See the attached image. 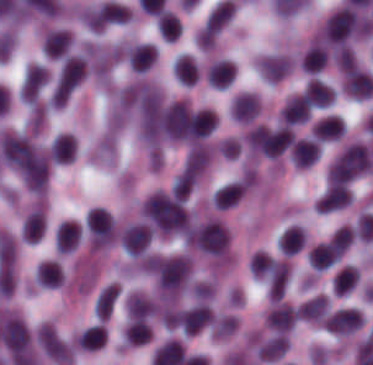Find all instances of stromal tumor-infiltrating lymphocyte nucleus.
I'll list each match as a JSON object with an SVG mask.
<instances>
[{
  "label": "stromal tumor-infiltrating lymphocyte nucleus",
  "mask_w": 373,
  "mask_h": 365,
  "mask_svg": "<svg viewBox=\"0 0 373 365\" xmlns=\"http://www.w3.org/2000/svg\"><path fill=\"white\" fill-rule=\"evenodd\" d=\"M34 280L45 287H58L63 282V269L57 259H44L36 265Z\"/></svg>",
  "instance_id": "obj_20"
},
{
  "label": "stromal tumor-infiltrating lymphocyte nucleus",
  "mask_w": 373,
  "mask_h": 365,
  "mask_svg": "<svg viewBox=\"0 0 373 365\" xmlns=\"http://www.w3.org/2000/svg\"><path fill=\"white\" fill-rule=\"evenodd\" d=\"M88 70L87 58L82 54L70 53L61 69L54 95L58 100H68Z\"/></svg>",
  "instance_id": "obj_3"
},
{
  "label": "stromal tumor-infiltrating lymphocyte nucleus",
  "mask_w": 373,
  "mask_h": 365,
  "mask_svg": "<svg viewBox=\"0 0 373 365\" xmlns=\"http://www.w3.org/2000/svg\"><path fill=\"white\" fill-rule=\"evenodd\" d=\"M296 319V309L289 302H276L265 317V323L276 333H287Z\"/></svg>",
  "instance_id": "obj_11"
},
{
  "label": "stromal tumor-infiltrating lymphocyte nucleus",
  "mask_w": 373,
  "mask_h": 365,
  "mask_svg": "<svg viewBox=\"0 0 373 365\" xmlns=\"http://www.w3.org/2000/svg\"><path fill=\"white\" fill-rule=\"evenodd\" d=\"M198 173L199 170L187 163L177 174L172 184V195L185 198L195 186Z\"/></svg>",
  "instance_id": "obj_25"
},
{
  "label": "stromal tumor-infiltrating lymphocyte nucleus",
  "mask_w": 373,
  "mask_h": 365,
  "mask_svg": "<svg viewBox=\"0 0 373 365\" xmlns=\"http://www.w3.org/2000/svg\"><path fill=\"white\" fill-rule=\"evenodd\" d=\"M47 74L48 69L41 64H28L19 90L25 103L35 106L47 81Z\"/></svg>",
  "instance_id": "obj_5"
},
{
  "label": "stromal tumor-infiltrating lymphocyte nucleus",
  "mask_w": 373,
  "mask_h": 365,
  "mask_svg": "<svg viewBox=\"0 0 373 365\" xmlns=\"http://www.w3.org/2000/svg\"><path fill=\"white\" fill-rule=\"evenodd\" d=\"M81 229L77 221H63L55 231L57 253H70L77 249L81 239Z\"/></svg>",
  "instance_id": "obj_14"
},
{
  "label": "stromal tumor-infiltrating lymphocyte nucleus",
  "mask_w": 373,
  "mask_h": 365,
  "mask_svg": "<svg viewBox=\"0 0 373 365\" xmlns=\"http://www.w3.org/2000/svg\"><path fill=\"white\" fill-rule=\"evenodd\" d=\"M343 132V120L340 115L328 113L311 126V137L321 141L337 139Z\"/></svg>",
  "instance_id": "obj_18"
},
{
  "label": "stromal tumor-infiltrating lymphocyte nucleus",
  "mask_w": 373,
  "mask_h": 365,
  "mask_svg": "<svg viewBox=\"0 0 373 365\" xmlns=\"http://www.w3.org/2000/svg\"><path fill=\"white\" fill-rule=\"evenodd\" d=\"M210 157L211 147L205 142H198L189 149L184 164L201 174L208 166Z\"/></svg>",
  "instance_id": "obj_28"
},
{
  "label": "stromal tumor-infiltrating lymphocyte nucleus",
  "mask_w": 373,
  "mask_h": 365,
  "mask_svg": "<svg viewBox=\"0 0 373 365\" xmlns=\"http://www.w3.org/2000/svg\"><path fill=\"white\" fill-rule=\"evenodd\" d=\"M320 142L312 137H299L292 144V160L297 168H308L319 158Z\"/></svg>",
  "instance_id": "obj_10"
},
{
  "label": "stromal tumor-infiltrating lymphocyte nucleus",
  "mask_w": 373,
  "mask_h": 365,
  "mask_svg": "<svg viewBox=\"0 0 373 365\" xmlns=\"http://www.w3.org/2000/svg\"><path fill=\"white\" fill-rule=\"evenodd\" d=\"M327 313V296L318 293L300 305L297 316L309 321H322Z\"/></svg>",
  "instance_id": "obj_24"
},
{
  "label": "stromal tumor-infiltrating lymphocyte nucleus",
  "mask_w": 373,
  "mask_h": 365,
  "mask_svg": "<svg viewBox=\"0 0 373 365\" xmlns=\"http://www.w3.org/2000/svg\"><path fill=\"white\" fill-rule=\"evenodd\" d=\"M238 326L236 318L229 313H221L214 319L212 333L214 338H224Z\"/></svg>",
  "instance_id": "obj_30"
},
{
  "label": "stromal tumor-infiltrating lymphocyte nucleus",
  "mask_w": 373,
  "mask_h": 365,
  "mask_svg": "<svg viewBox=\"0 0 373 365\" xmlns=\"http://www.w3.org/2000/svg\"><path fill=\"white\" fill-rule=\"evenodd\" d=\"M311 111V105L303 92H295L281 106L278 119L285 124L296 125L306 120Z\"/></svg>",
  "instance_id": "obj_7"
},
{
  "label": "stromal tumor-infiltrating lymphocyte nucleus",
  "mask_w": 373,
  "mask_h": 365,
  "mask_svg": "<svg viewBox=\"0 0 373 365\" xmlns=\"http://www.w3.org/2000/svg\"><path fill=\"white\" fill-rule=\"evenodd\" d=\"M305 245V235L299 225H292L282 232L277 248L282 254L292 255L303 249Z\"/></svg>",
  "instance_id": "obj_21"
},
{
  "label": "stromal tumor-infiltrating lymphocyte nucleus",
  "mask_w": 373,
  "mask_h": 365,
  "mask_svg": "<svg viewBox=\"0 0 373 365\" xmlns=\"http://www.w3.org/2000/svg\"><path fill=\"white\" fill-rule=\"evenodd\" d=\"M77 137L72 132H58L49 147L51 161L68 163L76 155Z\"/></svg>",
  "instance_id": "obj_13"
},
{
  "label": "stromal tumor-infiltrating lymphocyte nucleus",
  "mask_w": 373,
  "mask_h": 365,
  "mask_svg": "<svg viewBox=\"0 0 373 365\" xmlns=\"http://www.w3.org/2000/svg\"><path fill=\"white\" fill-rule=\"evenodd\" d=\"M36 343L43 352L61 365H71L73 359L72 343L52 323L45 322L35 331Z\"/></svg>",
  "instance_id": "obj_2"
},
{
  "label": "stromal tumor-infiltrating lymphocyte nucleus",
  "mask_w": 373,
  "mask_h": 365,
  "mask_svg": "<svg viewBox=\"0 0 373 365\" xmlns=\"http://www.w3.org/2000/svg\"><path fill=\"white\" fill-rule=\"evenodd\" d=\"M105 342V328L101 323H94L78 333L76 344L86 350L100 348Z\"/></svg>",
  "instance_id": "obj_26"
},
{
  "label": "stromal tumor-infiltrating lymphocyte nucleus",
  "mask_w": 373,
  "mask_h": 365,
  "mask_svg": "<svg viewBox=\"0 0 373 365\" xmlns=\"http://www.w3.org/2000/svg\"><path fill=\"white\" fill-rule=\"evenodd\" d=\"M291 274L289 260L276 259L268 277V296L270 300H280Z\"/></svg>",
  "instance_id": "obj_16"
},
{
  "label": "stromal tumor-infiltrating lymphocyte nucleus",
  "mask_w": 373,
  "mask_h": 365,
  "mask_svg": "<svg viewBox=\"0 0 373 365\" xmlns=\"http://www.w3.org/2000/svg\"><path fill=\"white\" fill-rule=\"evenodd\" d=\"M340 259V252L329 239L316 243L308 252V262L315 269H324L335 264Z\"/></svg>",
  "instance_id": "obj_19"
},
{
  "label": "stromal tumor-infiltrating lymphocyte nucleus",
  "mask_w": 373,
  "mask_h": 365,
  "mask_svg": "<svg viewBox=\"0 0 373 365\" xmlns=\"http://www.w3.org/2000/svg\"><path fill=\"white\" fill-rule=\"evenodd\" d=\"M120 241L124 253L138 256L143 253L152 240V228L143 222H136L123 228Z\"/></svg>",
  "instance_id": "obj_4"
},
{
  "label": "stromal tumor-infiltrating lymphocyte nucleus",
  "mask_w": 373,
  "mask_h": 365,
  "mask_svg": "<svg viewBox=\"0 0 373 365\" xmlns=\"http://www.w3.org/2000/svg\"><path fill=\"white\" fill-rule=\"evenodd\" d=\"M352 202V192L348 185L332 184L327 187L314 204L320 212H330Z\"/></svg>",
  "instance_id": "obj_9"
},
{
  "label": "stromal tumor-infiltrating lymphocyte nucleus",
  "mask_w": 373,
  "mask_h": 365,
  "mask_svg": "<svg viewBox=\"0 0 373 365\" xmlns=\"http://www.w3.org/2000/svg\"><path fill=\"white\" fill-rule=\"evenodd\" d=\"M250 185L249 178L244 177L234 180L215 190L213 205L221 208L235 206L245 194Z\"/></svg>",
  "instance_id": "obj_15"
},
{
  "label": "stromal tumor-infiltrating lymphocyte nucleus",
  "mask_w": 373,
  "mask_h": 365,
  "mask_svg": "<svg viewBox=\"0 0 373 365\" xmlns=\"http://www.w3.org/2000/svg\"><path fill=\"white\" fill-rule=\"evenodd\" d=\"M261 107V97L254 91H241L234 99L231 116L237 121L252 122Z\"/></svg>",
  "instance_id": "obj_8"
},
{
  "label": "stromal tumor-infiltrating lymphocyte nucleus",
  "mask_w": 373,
  "mask_h": 365,
  "mask_svg": "<svg viewBox=\"0 0 373 365\" xmlns=\"http://www.w3.org/2000/svg\"><path fill=\"white\" fill-rule=\"evenodd\" d=\"M324 322L335 334H349L363 324V313L358 308L345 306L326 316Z\"/></svg>",
  "instance_id": "obj_6"
},
{
  "label": "stromal tumor-infiltrating lymphocyte nucleus",
  "mask_w": 373,
  "mask_h": 365,
  "mask_svg": "<svg viewBox=\"0 0 373 365\" xmlns=\"http://www.w3.org/2000/svg\"><path fill=\"white\" fill-rule=\"evenodd\" d=\"M207 81L215 87H229L236 77L235 63L230 59H216L205 72Z\"/></svg>",
  "instance_id": "obj_17"
},
{
  "label": "stromal tumor-infiltrating lymphocyte nucleus",
  "mask_w": 373,
  "mask_h": 365,
  "mask_svg": "<svg viewBox=\"0 0 373 365\" xmlns=\"http://www.w3.org/2000/svg\"><path fill=\"white\" fill-rule=\"evenodd\" d=\"M157 308L155 301L140 292H133L130 294L125 303L128 317L136 319L148 317L153 314Z\"/></svg>",
  "instance_id": "obj_22"
},
{
  "label": "stromal tumor-infiltrating lymphocyte nucleus",
  "mask_w": 373,
  "mask_h": 365,
  "mask_svg": "<svg viewBox=\"0 0 373 365\" xmlns=\"http://www.w3.org/2000/svg\"><path fill=\"white\" fill-rule=\"evenodd\" d=\"M120 298V285L105 283L94 296L93 312L96 318L108 319Z\"/></svg>",
  "instance_id": "obj_12"
},
{
  "label": "stromal tumor-infiltrating lymphocyte nucleus",
  "mask_w": 373,
  "mask_h": 365,
  "mask_svg": "<svg viewBox=\"0 0 373 365\" xmlns=\"http://www.w3.org/2000/svg\"><path fill=\"white\" fill-rule=\"evenodd\" d=\"M373 170V156L369 147L353 142L339 154L328 169V182L353 180Z\"/></svg>",
  "instance_id": "obj_1"
},
{
  "label": "stromal tumor-infiltrating lymphocyte nucleus",
  "mask_w": 373,
  "mask_h": 365,
  "mask_svg": "<svg viewBox=\"0 0 373 365\" xmlns=\"http://www.w3.org/2000/svg\"><path fill=\"white\" fill-rule=\"evenodd\" d=\"M183 24L174 11L161 10L157 14V31L171 42L182 34Z\"/></svg>",
  "instance_id": "obj_23"
},
{
  "label": "stromal tumor-infiltrating lymphocyte nucleus",
  "mask_w": 373,
  "mask_h": 365,
  "mask_svg": "<svg viewBox=\"0 0 373 365\" xmlns=\"http://www.w3.org/2000/svg\"><path fill=\"white\" fill-rule=\"evenodd\" d=\"M274 265L271 254L263 250H256L251 254L250 271L255 276H271Z\"/></svg>",
  "instance_id": "obj_29"
},
{
  "label": "stromal tumor-infiltrating lymphocyte nucleus",
  "mask_w": 373,
  "mask_h": 365,
  "mask_svg": "<svg viewBox=\"0 0 373 365\" xmlns=\"http://www.w3.org/2000/svg\"><path fill=\"white\" fill-rule=\"evenodd\" d=\"M125 342L129 345H140L151 338V330L145 318H137L126 323L124 327Z\"/></svg>",
  "instance_id": "obj_27"
}]
</instances>
